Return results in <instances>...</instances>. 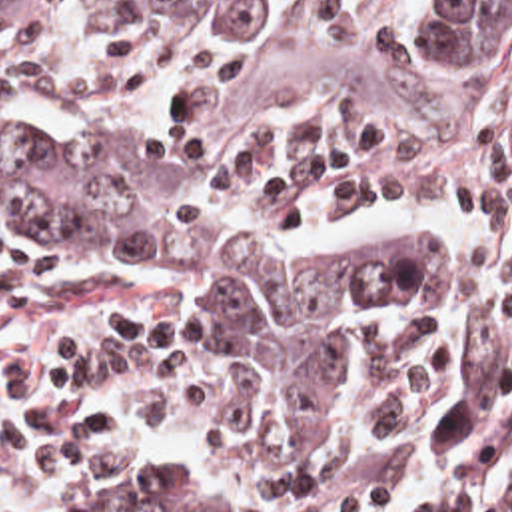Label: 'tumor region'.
<instances>
[{"label": "tumor region", "mask_w": 512, "mask_h": 512, "mask_svg": "<svg viewBox=\"0 0 512 512\" xmlns=\"http://www.w3.org/2000/svg\"><path fill=\"white\" fill-rule=\"evenodd\" d=\"M0 0L55 17H161L239 47L261 101L327 111H490L512 101V0ZM0 229L81 271L133 267L229 311L295 451L321 443L333 333L354 303L434 281V233L378 229L321 257H267L107 179L53 139L0 135Z\"/></svg>", "instance_id": "tumor-region-1"}]
</instances>
